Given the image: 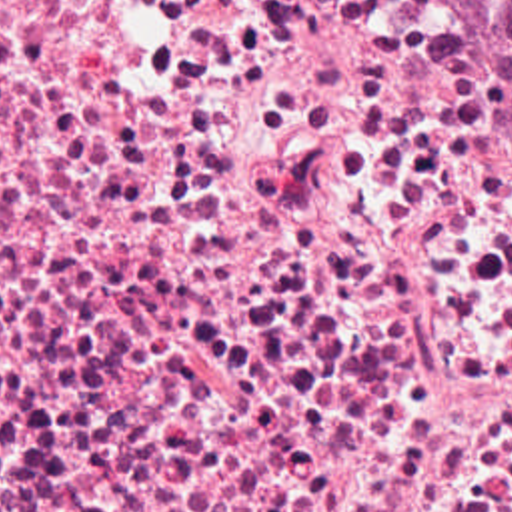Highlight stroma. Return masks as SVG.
<instances>
[{"mask_svg": "<svg viewBox=\"0 0 512 512\" xmlns=\"http://www.w3.org/2000/svg\"><path fill=\"white\" fill-rule=\"evenodd\" d=\"M0 512H512V428H0Z\"/></svg>", "mask_w": 512, "mask_h": 512, "instance_id": "stroma-1", "label": "stroma"}]
</instances>
